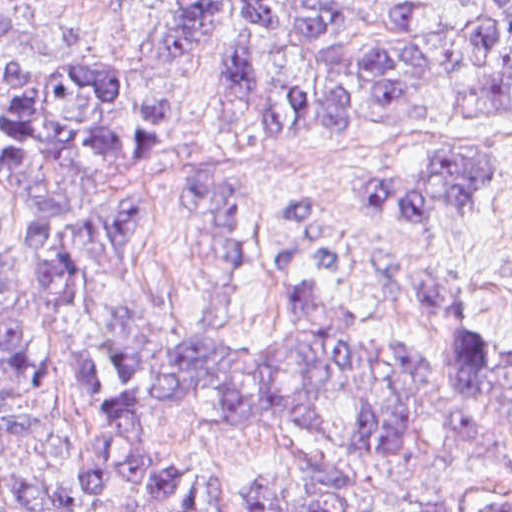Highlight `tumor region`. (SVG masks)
Instances as JSON below:
<instances>
[{
  "instance_id": "obj_1",
  "label": "tumor region",
  "mask_w": 512,
  "mask_h": 512,
  "mask_svg": "<svg viewBox=\"0 0 512 512\" xmlns=\"http://www.w3.org/2000/svg\"><path fill=\"white\" fill-rule=\"evenodd\" d=\"M149 39L158 63L201 59L214 123L246 134H318L338 118L411 117L438 91L473 114L512 109V0H161ZM36 0H0V182L18 202L16 245L0 237V434L49 432L6 405L26 391L33 354L23 307L57 317L73 288L104 293L137 221L129 202L84 207L94 166L133 165L140 155L96 73L75 65L25 68L11 33L46 21ZM151 153L172 126L165 95L141 102ZM495 157L440 155L403 176H369L360 192L418 223L446 219L480 198ZM435 338L472 307L456 276H419L390 288ZM281 327L263 335L209 333L231 356L257 362H329L305 372H209L196 333L157 313L117 318L107 360L109 396L88 359H64L73 401L102 427L81 441L82 499L125 512H219L208 466L166 451L157 415L175 402H205L234 424L296 423L338 436L334 415L368 402L362 452L389 454L407 442L404 416L433 395L460 397L450 416L471 441L492 415H512V353L440 346L362 344L329 285L296 286L278 297ZM259 512H331L304 490H248ZM0 512H58L49 486L0 457Z\"/></svg>"
}]
</instances>
